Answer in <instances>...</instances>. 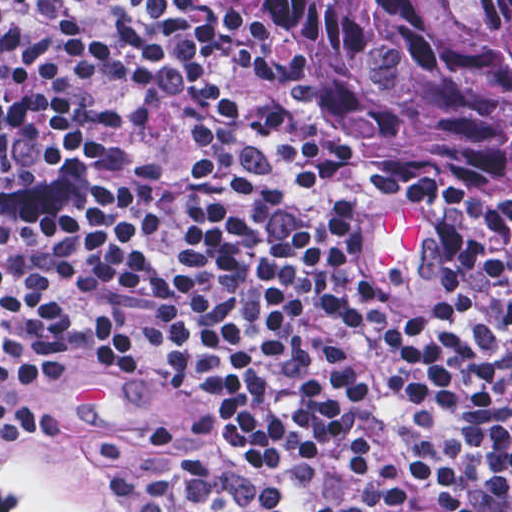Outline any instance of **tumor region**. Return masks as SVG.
I'll return each mask as SVG.
<instances>
[{"mask_svg":"<svg viewBox=\"0 0 512 512\" xmlns=\"http://www.w3.org/2000/svg\"><path fill=\"white\" fill-rule=\"evenodd\" d=\"M391 209L512 237V0H267Z\"/></svg>","mask_w":512,"mask_h":512,"instance_id":"obj_1","label":"tumor region"}]
</instances>
